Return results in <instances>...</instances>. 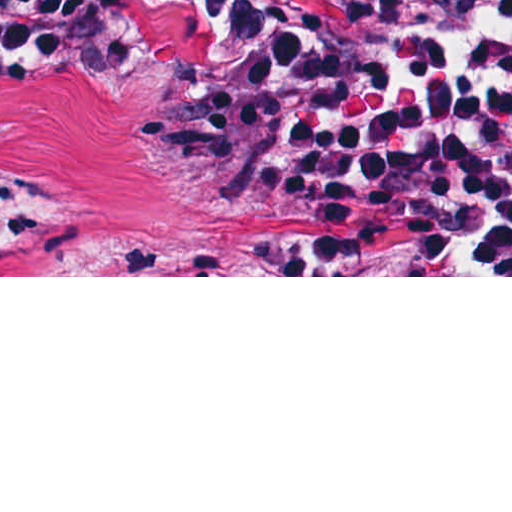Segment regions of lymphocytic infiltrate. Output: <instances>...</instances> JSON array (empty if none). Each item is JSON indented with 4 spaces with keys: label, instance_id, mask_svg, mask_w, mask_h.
Listing matches in <instances>:
<instances>
[{
    "label": "lymphocytic infiltrate",
    "instance_id": "f902f5d3",
    "mask_svg": "<svg viewBox=\"0 0 512 512\" xmlns=\"http://www.w3.org/2000/svg\"><path fill=\"white\" fill-rule=\"evenodd\" d=\"M165 17L265 67L262 102L194 138L245 204L512 275V0H0V60L94 82ZM32 238L0 184V268Z\"/></svg>",
    "mask_w": 512,
    "mask_h": 512
}]
</instances>
